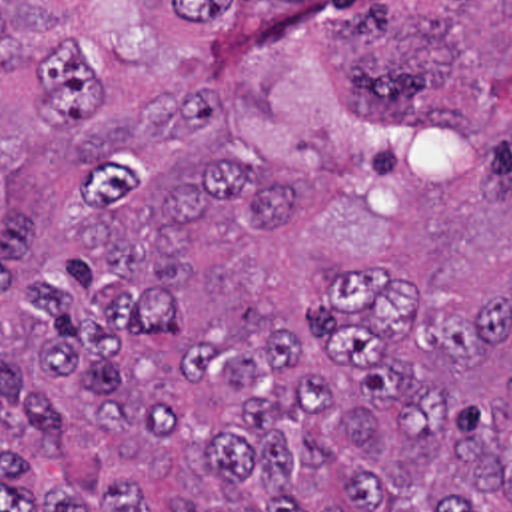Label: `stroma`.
Instances as JSON below:
<instances>
[{
  "label": "stroma",
  "mask_w": 512,
  "mask_h": 512,
  "mask_svg": "<svg viewBox=\"0 0 512 512\" xmlns=\"http://www.w3.org/2000/svg\"><path fill=\"white\" fill-rule=\"evenodd\" d=\"M439 0H373L371 31L385 43L419 25Z\"/></svg>",
  "instance_id": "stroma-1"
}]
</instances>
